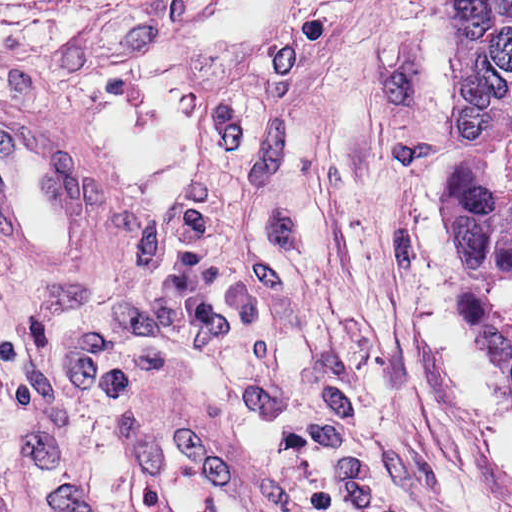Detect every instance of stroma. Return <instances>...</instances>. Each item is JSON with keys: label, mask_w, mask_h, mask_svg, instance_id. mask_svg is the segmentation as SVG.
<instances>
[{"label": "stroma", "mask_w": 512, "mask_h": 512, "mask_svg": "<svg viewBox=\"0 0 512 512\" xmlns=\"http://www.w3.org/2000/svg\"><path fill=\"white\" fill-rule=\"evenodd\" d=\"M86 137L85 265L0 248V512H149L146 403L278 512H487L259 0H0V98Z\"/></svg>", "instance_id": "35a3bbf8"}]
</instances>
